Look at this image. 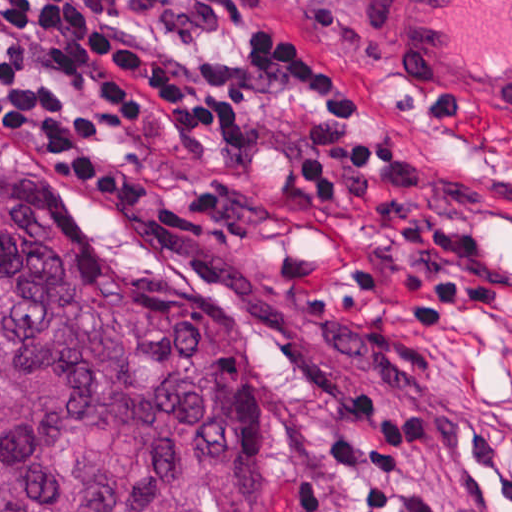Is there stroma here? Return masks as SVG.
<instances>
[{"instance_id": "1", "label": "stroma", "mask_w": 512, "mask_h": 512, "mask_svg": "<svg viewBox=\"0 0 512 512\" xmlns=\"http://www.w3.org/2000/svg\"><path fill=\"white\" fill-rule=\"evenodd\" d=\"M131 42L234 95L244 144L186 149L148 199H113L44 163L0 115V141L37 176L102 203L131 248L188 296L247 327L263 416L234 460L250 512H368L331 402L374 385L393 412L430 402L435 432L402 469L445 512H512V145L424 116L388 71L361 0H94ZM275 31L339 70L361 110L350 135L399 154L313 197L299 172L322 104L258 76Z\"/></svg>"}]
</instances>
